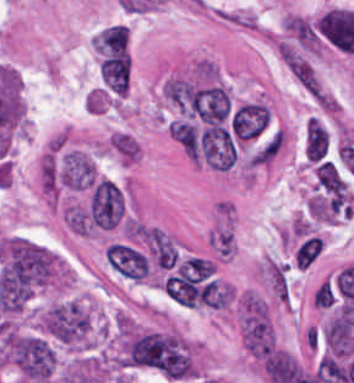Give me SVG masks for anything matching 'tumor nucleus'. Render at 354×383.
<instances>
[{"label": "tumor nucleus", "instance_id": "2f306a5c", "mask_svg": "<svg viewBox=\"0 0 354 383\" xmlns=\"http://www.w3.org/2000/svg\"><path fill=\"white\" fill-rule=\"evenodd\" d=\"M40 324L63 344L81 346L88 344L92 319L84 301L70 298L49 304L40 316Z\"/></svg>", "mask_w": 354, "mask_h": 383}]
</instances>
